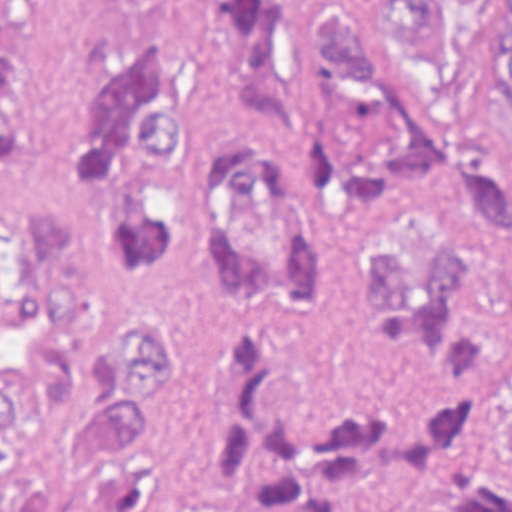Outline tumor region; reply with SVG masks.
Here are the masks:
<instances>
[{
  "mask_svg": "<svg viewBox=\"0 0 512 512\" xmlns=\"http://www.w3.org/2000/svg\"><path fill=\"white\" fill-rule=\"evenodd\" d=\"M279 0H188L167 46L102 59L67 161L0 215V512H512V191L373 233L356 274L417 362L401 403L284 390L239 338L203 391L191 291L290 327L337 318L268 138ZM413 87L319 8L294 110L334 210L384 218L426 178L512 182V0H375ZM23 120V16L0 0V150Z\"/></svg>",
  "mask_w": 512,
  "mask_h": 512,
  "instance_id": "e687c5a6",
  "label": "tumor region"
}]
</instances>
